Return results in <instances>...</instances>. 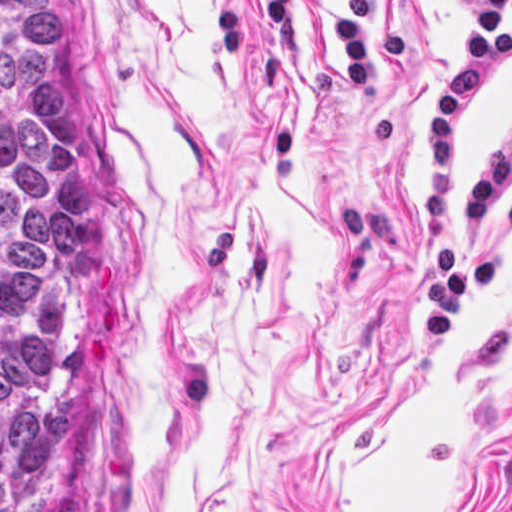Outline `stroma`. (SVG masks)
Returning <instances> with one entry per match:
<instances>
[{"instance_id":"obj_1","label":"stroma","mask_w":512,"mask_h":512,"mask_svg":"<svg viewBox=\"0 0 512 512\" xmlns=\"http://www.w3.org/2000/svg\"><path fill=\"white\" fill-rule=\"evenodd\" d=\"M96 163L80 406L46 512H512V176L498 278L443 343L423 270L456 0H378L414 63L354 99L329 0L282 59L258 0H41ZM512 119H466L450 200Z\"/></svg>"}]
</instances>
